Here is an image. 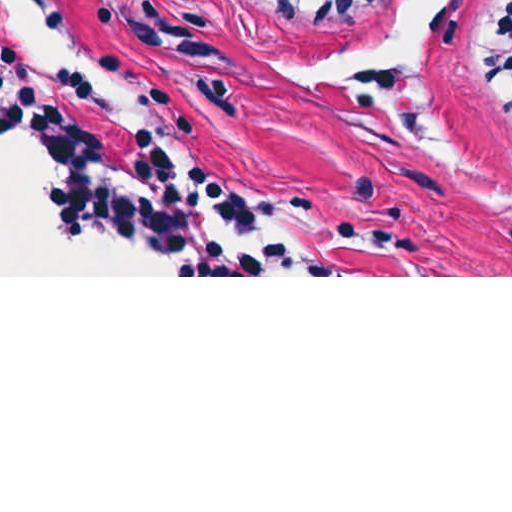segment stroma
<instances>
[{"label": "stroma", "mask_w": 512, "mask_h": 512, "mask_svg": "<svg viewBox=\"0 0 512 512\" xmlns=\"http://www.w3.org/2000/svg\"><path fill=\"white\" fill-rule=\"evenodd\" d=\"M55 1L144 126L164 132L183 177L194 165L207 169L263 221L259 233L212 223L216 231L280 238L337 275L0 277H512V209L379 100L299 81L306 63L358 44L407 0H382L342 25H293L253 0ZM506 1H453L432 96L471 150L512 170V122L499 93L480 82ZM21 64L38 94L49 77ZM73 109L115 164L126 158L138 135L100 118L90 95ZM50 171L46 148V186Z\"/></svg>", "instance_id": "35a3bbf8"}]
</instances>
